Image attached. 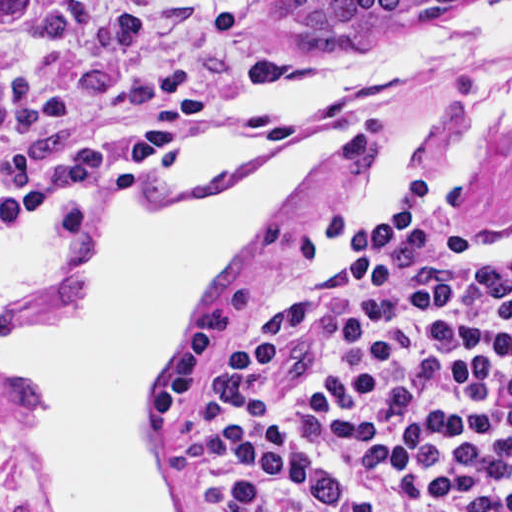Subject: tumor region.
Returning <instances> with one entry per match:
<instances>
[{
  "mask_svg": "<svg viewBox=\"0 0 512 512\" xmlns=\"http://www.w3.org/2000/svg\"><path fill=\"white\" fill-rule=\"evenodd\" d=\"M408 1H310L305 8L309 28H339L363 13L405 4Z\"/></svg>",
  "mask_w": 512,
  "mask_h": 512,
  "instance_id": "tumor-region-1",
  "label": "tumor region"
}]
</instances>
